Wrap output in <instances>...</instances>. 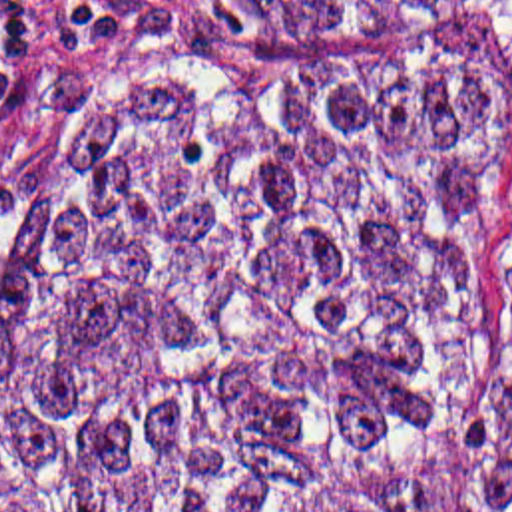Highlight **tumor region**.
<instances>
[{
    "label": "tumor region",
    "mask_w": 512,
    "mask_h": 512,
    "mask_svg": "<svg viewBox=\"0 0 512 512\" xmlns=\"http://www.w3.org/2000/svg\"><path fill=\"white\" fill-rule=\"evenodd\" d=\"M492 0H209L411 44ZM464 56H193L66 125L0 249V512H424L502 249ZM512 512V332L472 482Z\"/></svg>",
    "instance_id": "obj_1"
}]
</instances>
